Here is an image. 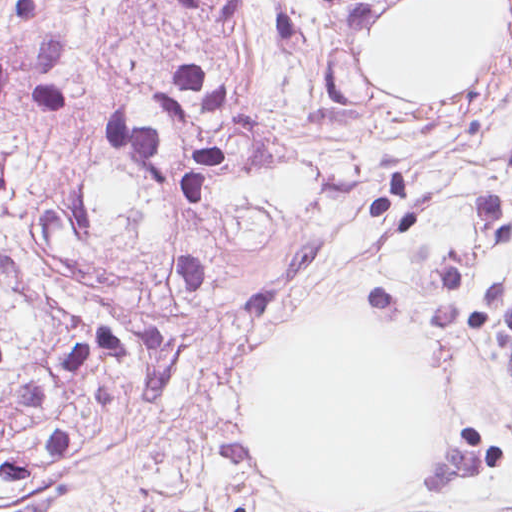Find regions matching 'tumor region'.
I'll return each mask as SVG.
<instances>
[{"mask_svg": "<svg viewBox=\"0 0 512 512\" xmlns=\"http://www.w3.org/2000/svg\"><path fill=\"white\" fill-rule=\"evenodd\" d=\"M396 0H0V403L140 330L202 371L368 313L512 394V151L483 85L384 100Z\"/></svg>", "mask_w": 512, "mask_h": 512, "instance_id": "e687c5a6", "label": "tumor region"}]
</instances>
